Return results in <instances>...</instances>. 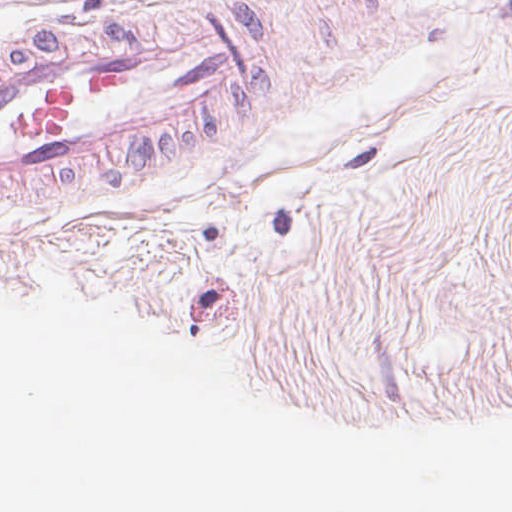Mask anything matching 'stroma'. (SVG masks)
Segmentation results:
<instances>
[{
  "mask_svg": "<svg viewBox=\"0 0 512 512\" xmlns=\"http://www.w3.org/2000/svg\"><path fill=\"white\" fill-rule=\"evenodd\" d=\"M0 7L512 173V0Z\"/></svg>",
  "mask_w": 512,
  "mask_h": 512,
  "instance_id": "stroma-1",
  "label": "stroma"
}]
</instances>
